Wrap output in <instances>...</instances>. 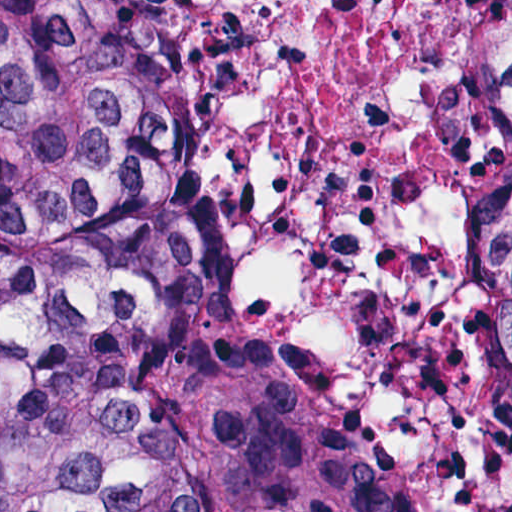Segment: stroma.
Returning a JSON list of instances; mask_svg holds the SVG:
<instances>
[{"instance_id": "obj_1", "label": "stroma", "mask_w": 512, "mask_h": 512, "mask_svg": "<svg viewBox=\"0 0 512 512\" xmlns=\"http://www.w3.org/2000/svg\"><path fill=\"white\" fill-rule=\"evenodd\" d=\"M314 406L346 468L380 512H411L361 415L325 395L302 368Z\"/></svg>"}]
</instances>
